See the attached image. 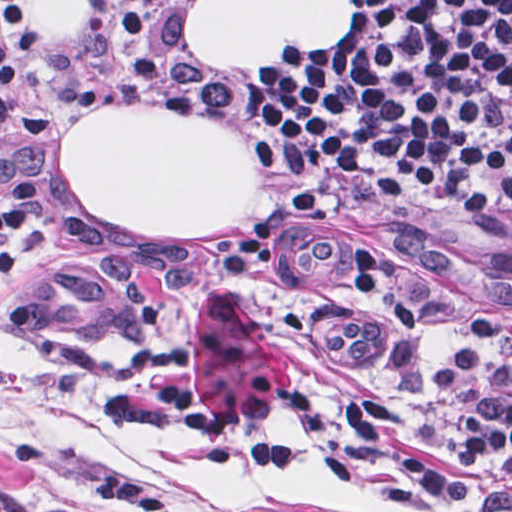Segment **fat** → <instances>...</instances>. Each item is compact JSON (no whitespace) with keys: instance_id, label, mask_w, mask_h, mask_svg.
Segmentation results:
<instances>
[{"instance_id":"fat-1","label":"fat","mask_w":512,"mask_h":512,"mask_svg":"<svg viewBox=\"0 0 512 512\" xmlns=\"http://www.w3.org/2000/svg\"><path fill=\"white\" fill-rule=\"evenodd\" d=\"M91 0H39L51 39H77ZM350 0H196L189 43L213 67H281L290 53L343 37ZM64 174L101 224L153 236H209L255 210L244 140L185 108L84 112L68 129Z\"/></svg>"}]
</instances>
